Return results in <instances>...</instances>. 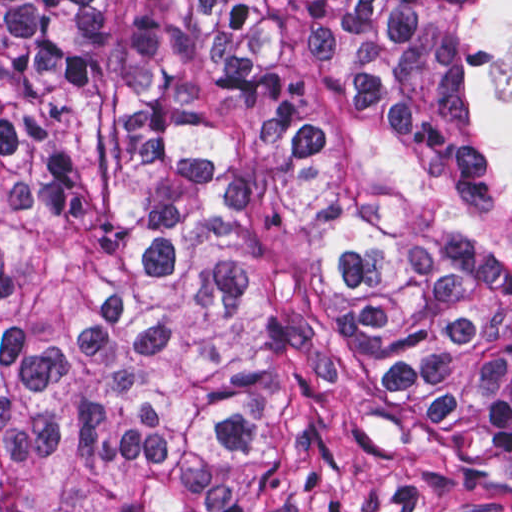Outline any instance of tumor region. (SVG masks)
<instances>
[{"instance_id": "e687c5a6", "label": "tumor region", "mask_w": 512, "mask_h": 512, "mask_svg": "<svg viewBox=\"0 0 512 512\" xmlns=\"http://www.w3.org/2000/svg\"><path fill=\"white\" fill-rule=\"evenodd\" d=\"M0 512H512V0H0Z\"/></svg>"}]
</instances>
